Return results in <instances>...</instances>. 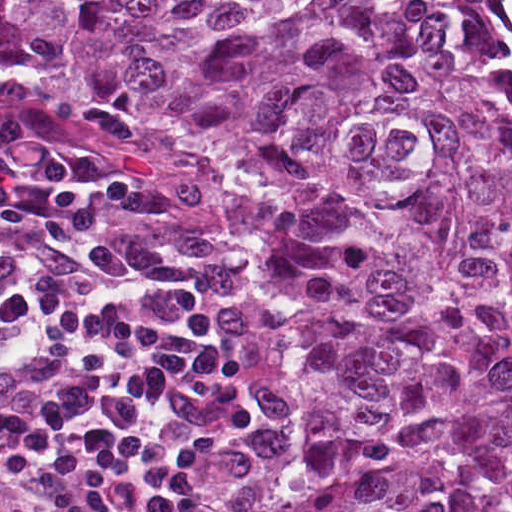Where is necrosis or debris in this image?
I'll use <instances>...</instances> for the list:
<instances>
[{"mask_svg": "<svg viewBox=\"0 0 512 512\" xmlns=\"http://www.w3.org/2000/svg\"><path fill=\"white\" fill-rule=\"evenodd\" d=\"M449 19L512 98V0H449Z\"/></svg>", "mask_w": 512, "mask_h": 512, "instance_id": "1", "label": "necrosis or debris"}]
</instances>
